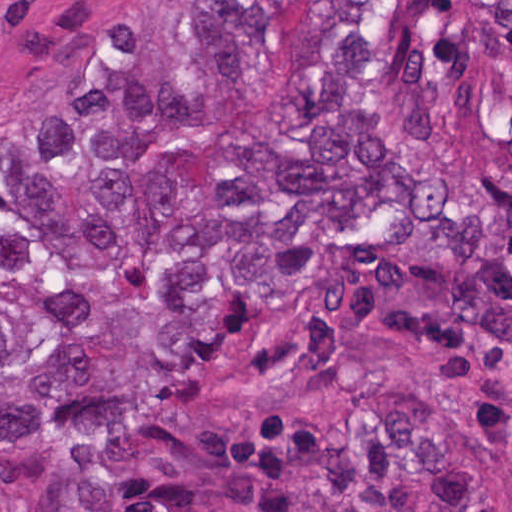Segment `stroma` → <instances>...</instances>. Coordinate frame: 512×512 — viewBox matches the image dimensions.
I'll return each mask as SVG.
<instances>
[{
  "label": "stroma",
  "mask_w": 512,
  "mask_h": 512,
  "mask_svg": "<svg viewBox=\"0 0 512 512\" xmlns=\"http://www.w3.org/2000/svg\"><path fill=\"white\" fill-rule=\"evenodd\" d=\"M123 1L512 0H0V118L41 99ZM391 389H409L471 444L492 512H512V343L482 327L456 271L428 262L406 234L377 254L335 259L316 310L248 319L200 419ZM53 469L47 438L0 443V512H34Z\"/></svg>",
  "instance_id": "35a3bbf8"
}]
</instances>
